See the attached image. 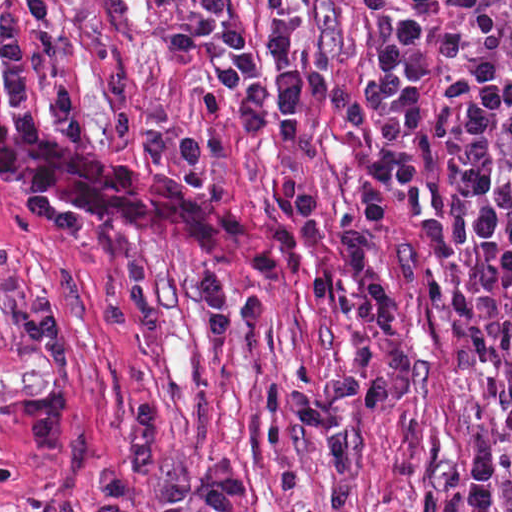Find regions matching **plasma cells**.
Masks as SVG:
<instances>
[{
  "instance_id": "1",
  "label": "plasma cells",
  "mask_w": 512,
  "mask_h": 512,
  "mask_svg": "<svg viewBox=\"0 0 512 512\" xmlns=\"http://www.w3.org/2000/svg\"><path fill=\"white\" fill-rule=\"evenodd\" d=\"M313 2L264 0L271 19ZM109 85L116 136L140 132L156 163H175L187 182L209 192L227 244L241 263L272 279H291L301 255L319 240L320 230V201L304 190L299 175L288 173L278 196L280 225L261 230L243 210L231 185L214 176L215 165L229 155L220 133L175 128L167 104L141 107L123 69H115ZM51 110L67 146L86 147L84 123L69 89L55 88ZM446 135L470 243L486 254L512 258V0L481 16L455 44L446 81ZM389 182L386 169L374 170L359 193L362 216L346 212L339 221L345 259L362 289L358 311L378 337L379 370L354 321L343 284L334 277H316L309 285L311 302L350 327L354 367L350 373L328 376L317 389H297L288 397L292 420L331 451L329 512L347 506L363 468L342 412L358 403L380 407L412 381L413 351L404 315L378 247L386 223L378 191ZM195 295L214 340L234 329L229 309L250 325H265L271 319L263 292L258 289L236 299L230 280L211 266L200 271Z\"/></svg>"
}]
</instances>
